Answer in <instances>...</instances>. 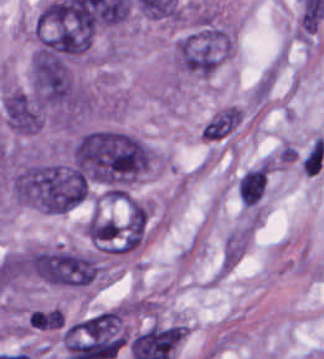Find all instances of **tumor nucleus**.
I'll use <instances>...</instances> for the list:
<instances>
[{"mask_svg":"<svg viewBox=\"0 0 324 359\" xmlns=\"http://www.w3.org/2000/svg\"><path fill=\"white\" fill-rule=\"evenodd\" d=\"M151 155L136 133L103 125L77 132L70 144L74 166L103 189H123L137 180Z\"/></svg>","mask_w":324,"mask_h":359,"instance_id":"2f306a5c","label":"tumor nucleus"},{"mask_svg":"<svg viewBox=\"0 0 324 359\" xmlns=\"http://www.w3.org/2000/svg\"><path fill=\"white\" fill-rule=\"evenodd\" d=\"M29 85L45 123L75 124L93 108L89 86L60 52L40 40L29 65Z\"/></svg>","mask_w":324,"mask_h":359,"instance_id":"8643909e","label":"tumor nucleus"},{"mask_svg":"<svg viewBox=\"0 0 324 359\" xmlns=\"http://www.w3.org/2000/svg\"><path fill=\"white\" fill-rule=\"evenodd\" d=\"M15 272L60 288L78 289L99 280L104 265L91 250L55 245L16 252Z\"/></svg>","mask_w":324,"mask_h":359,"instance_id":"5ab6c2c4","label":"tumor nucleus"},{"mask_svg":"<svg viewBox=\"0 0 324 359\" xmlns=\"http://www.w3.org/2000/svg\"><path fill=\"white\" fill-rule=\"evenodd\" d=\"M88 181L65 161L30 160L23 167V201L45 212H65L86 196Z\"/></svg>","mask_w":324,"mask_h":359,"instance_id":"2cbd58db","label":"tumor nucleus"},{"mask_svg":"<svg viewBox=\"0 0 324 359\" xmlns=\"http://www.w3.org/2000/svg\"><path fill=\"white\" fill-rule=\"evenodd\" d=\"M234 52L231 30L215 21H201L173 43L172 63L180 72L207 77Z\"/></svg>","mask_w":324,"mask_h":359,"instance_id":"3d1891a8","label":"tumor nucleus"},{"mask_svg":"<svg viewBox=\"0 0 324 359\" xmlns=\"http://www.w3.org/2000/svg\"><path fill=\"white\" fill-rule=\"evenodd\" d=\"M0 108L7 127L14 133L32 134L41 124V116L27 89L4 84L0 88Z\"/></svg>","mask_w":324,"mask_h":359,"instance_id":"2083b535","label":"tumor nucleus"},{"mask_svg":"<svg viewBox=\"0 0 324 359\" xmlns=\"http://www.w3.org/2000/svg\"><path fill=\"white\" fill-rule=\"evenodd\" d=\"M240 108L225 106L210 116L200 129V136L209 141L224 139L241 123Z\"/></svg>","mask_w":324,"mask_h":359,"instance_id":"8087334f","label":"tumor nucleus"}]
</instances>
